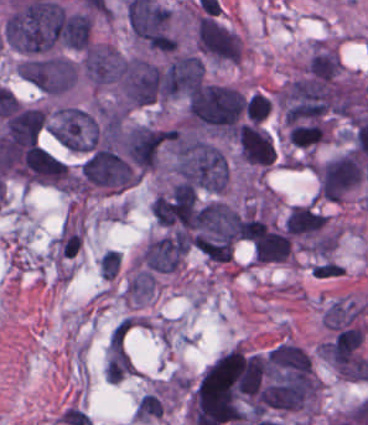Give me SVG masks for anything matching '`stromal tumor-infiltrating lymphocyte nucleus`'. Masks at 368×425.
<instances>
[{
    "mask_svg": "<svg viewBox=\"0 0 368 425\" xmlns=\"http://www.w3.org/2000/svg\"><path fill=\"white\" fill-rule=\"evenodd\" d=\"M322 138V124L318 120H310L292 124L288 128V141L296 146H307L319 142Z\"/></svg>",
    "mask_w": 368,
    "mask_h": 425,
    "instance_id": "stromal-tumor-infiltrating-lymphocyte-nucleus-1",
    "label": "stromal tumor-infiltrating lymphocyte nucleus"
}]
</instances>
